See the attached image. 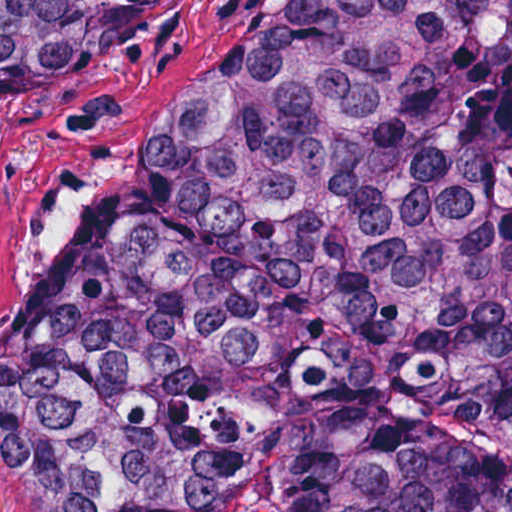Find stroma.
I'll use <instances>...</instances> for the list:
<instances>
[{"label":"stroma","mask_w":512,"mask_h":512,"mask_svg":"<svg viewBox=\"0 0 512 512\" xmlns=\"http://www.w3.org/2000/svg\"><path fill=\"white\" fill-rule=\"evenodd\" d=\"M271 0H174L38 93H0V323L93 197L122 126L179 77L241 67ZM0 512H42L0 471Z\"/></svg>","instance_id":"obj_1"}]
</instances>
